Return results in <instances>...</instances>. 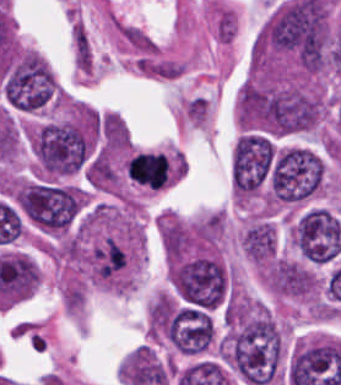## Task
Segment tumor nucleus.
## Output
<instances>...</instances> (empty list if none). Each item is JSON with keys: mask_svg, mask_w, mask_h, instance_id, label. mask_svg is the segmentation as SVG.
<instances>
[{"mask_svg": "<svg viewBox=\"0 0 341 385\" xmlns=\"http://www.w3.org/2000/svg\"><path fill=\"white\" fill-rule=\"evenodd\" d=\"M20 209L38 228L51 233H64L78 218L83 194L70 185L30 179L18 186Z\"/></svg>", "mask_w": 341, "mask_h": 385, "instance_id": "obj_1", "label": "tumor nucleus"}, {"mask_svg": "<svg viewBox=\"0 0 341 385\" xmlns=\"http://www.w3.org/2000/svg\"><path fill=\"white\" fill-rule=\"evenodd\" d=\"M324 174L325 164L316 152L289 147L273 167L278 203L303 201L319 189Z\"/></svg>", "mask_w": 341, "mask_h": 385, "instance_id": "obj_2", "label": "tumor nucleus"}, {"mask_svg": "<svg viewBox=\"0 0 341 385\" xmlns=\"http://www.w3.org/2000/svg\"><path fill=\"white\" fill-rule=\"evenodd\" d=\"M293 245L306 261L326 264L341 254V225L323 207H310L294 222Z\"/></svg>", "mask_w": 341, "mask_h": 385, "instance_id": "obj_3", "label": "tumor nucleus"}, {"mask_svg": "<svg viewBox=\"0 0 341 385\" xmlns=\"http://www.w3.org/2000/svg\"><path fill=\"white\" fill-rule=\"evenodd\" d=\"M130 178L140 185L160 189L166 184V157L161 151H142L132 154L125 166Z\"/></svg>", "mask_w": 341, "mask_h": 385, "instance_id": "obj_4", "label": "tumor nucleus"}, {"mask_svg": "<svg viewBox=\"0 0 341 385\" xmlns=\"http://www.w3.org/2000/svg\"><path fill=\"white\" fill-rule=\"evenodd\" d=\"M277 246L276 231L264 217H257L241 234V248L256 262H266L275 254Z\"/></svg>", "mask_w": 341, "mask_h": 385, "instance_id": "obj_5", "label": "tumor nucleus"}]
</instances>
